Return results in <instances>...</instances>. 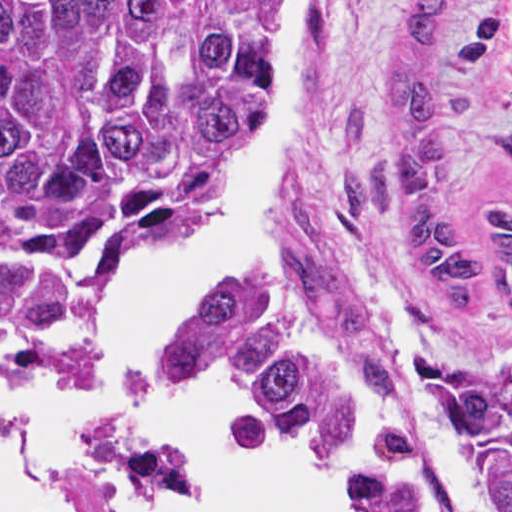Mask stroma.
<instances>
[{"label": "stroma", "instance_id": "obj_1", "mask_svg": "<svg viewBox=\"0 0 512 512\" xmlns=\"http://www.w3.org/2000/svg\"><path fill=\"white\" fill-rule=\"evenodd\" d=\"M407 1L304 2L278 247L290 279L269 295L410 418L450 512H472L442 438V385L512 337L503 271L478 247L479 311L453 309L408 263L400 220L346 204L354 172L393 154L383 115ZM439 132L444 212L482 232L488 206H512V0H457L439 46Z\"/></svg>", "mask_w": 512, "mask_h": 512}]
</instances>
